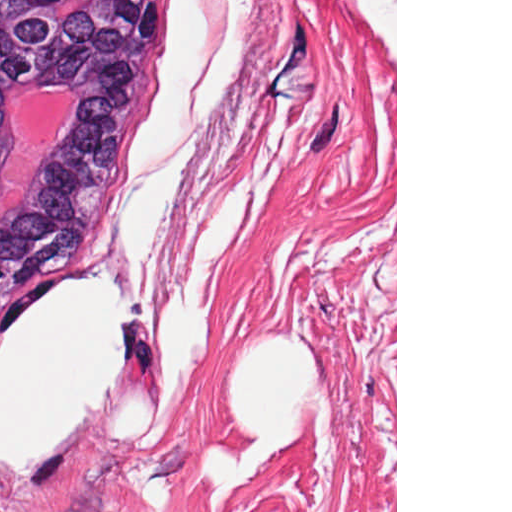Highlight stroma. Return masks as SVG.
<instances>
[{
  "label": "stroma",
  "mask_w": 512,
  "mask_h": 512,
  "mask_svg": "<svg viewBox=\"0 0 512 512\" xmlns=\"http://www.w3.org/2000/svg\"><path fill=\"white\" fill-rule=\"evenodd\" d=\"M175 0L118 153L58 266L120 285L124 367L52 459L0 467V512H224L279 0H210L201 81L181 140L128 176ZM197 128L186 190L139 295L117 255L135 180Z\"/></svg>",
  "instance_id": "obj_1"
}]
</instances>
